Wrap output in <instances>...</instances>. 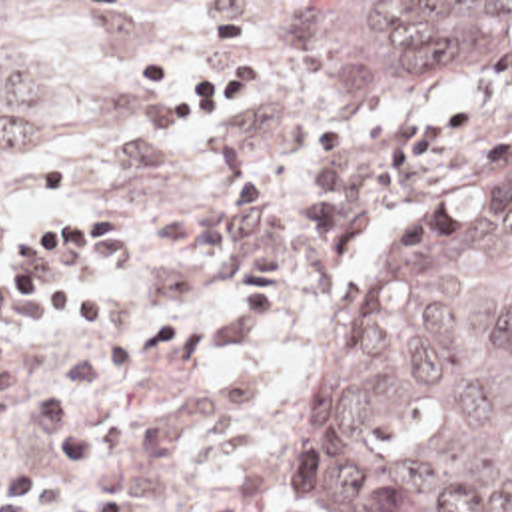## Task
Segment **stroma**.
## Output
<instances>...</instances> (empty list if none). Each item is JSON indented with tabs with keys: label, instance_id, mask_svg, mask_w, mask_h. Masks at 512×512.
Listing matches in <instances>:
<instances>
[{
	"label": "stroma",
	"instance_id": "35a3bbf8",
	"mask_svg": "<svg viewBox=\"0 0 512 512\" xmlns=\"http://www.w3.org/2000/svg\"><path fill=\"white\" fill-rule=\"evenodd\" d=\"M0 2L69 8L121 70L103 172L61 218L131 208V236L93 264L115 308L105 325L61 337L39 304L17 302L37 331L15 351L53 349L67 375L143 341V369L91 405L95 465L51 455L25 421L0 427V512L19 489L59 503L121 477L137 512L221 499L299 512L305 419L372 270L484 154L512 144V64L424 108L333 102L311 74L297 2L512 0ZM27 100L43 156L0 202V246L11 212L55 182L63 96L45 66Z\"/></svg>",
	"mask_w": 512,
	"mask_h": 512
}]
</instances>
